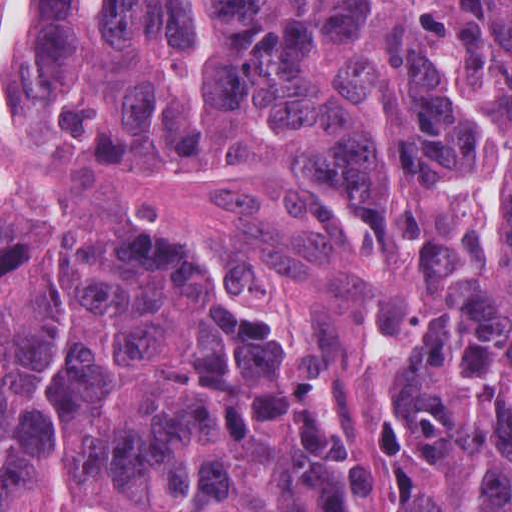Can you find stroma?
I'll return each mask as SVG.
<instances>
[{"label":"stroma","instance_id":"stroma-1","mask_svg":"<svg viewBox=\"0 0 512 512\" xmlns=\"http://www.w3.org/2000/svg\"><path fill=\"white\" fill-rule=\"evenodd\" d=\"M11 1L0 0V14ZM9 110H0V512L1 194L147 217L196 236L242 303L295 331L362 512H402L378 286L348 209L321 189L271 172L143 177L79 155L23 148L1 139V114Z\"/></svg>","mask_w":512,"mask_h":512}]
</instances>
